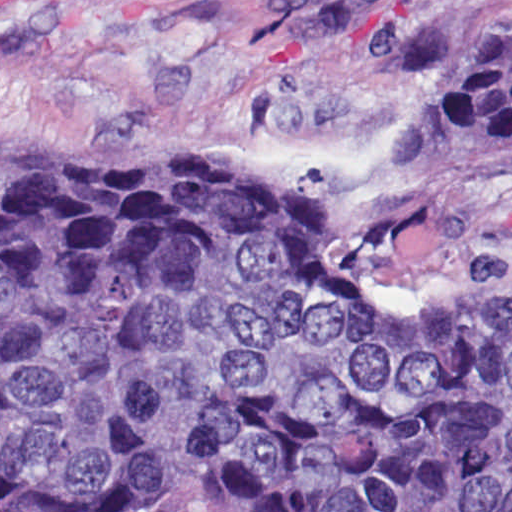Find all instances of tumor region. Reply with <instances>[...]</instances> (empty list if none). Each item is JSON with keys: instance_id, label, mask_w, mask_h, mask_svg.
<instances>
[{"instance_id": "1", "label": "tumor region", "mask_w": 512, "mask_h": 512, "mask_svg": "<svg viewBox=\"0 0 512 512\" xmlns=\"http://www.w3.org/2000/svg\"><path fill=\"white\" fill-rule=\"evenodd\" d=\"M452 137L512 148V0ZM512 512V286L394 316L312 189L234 166H0V512Z\"/></svg>"}]
</instances>
